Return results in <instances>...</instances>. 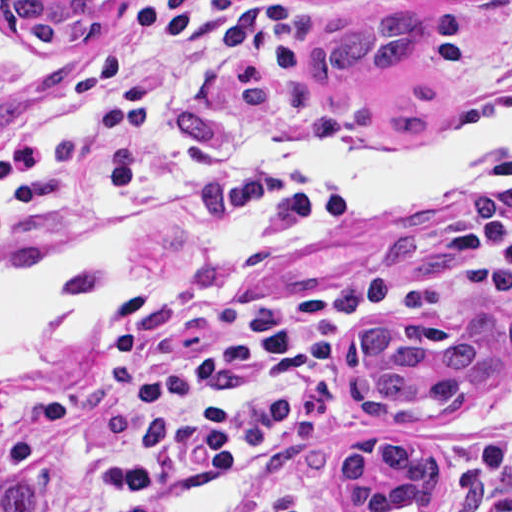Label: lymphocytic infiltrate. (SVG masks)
<instances>
[{
  "mask_svg": "<svg viewBox=\"0 0 512 512\" xmlns=\"http://www.w3.org/2000/svg\"><path fill=\"white\" fill-rule=\"evenodd\" d=\"M298 12L296 0L118 5L92 62L44 122L0 137V246L92 222L122 197L158 199L236 230L278 214L330 218L344 208L346 192L305 164L414 143L388 138L380 125L323 119L293 53ZM510 97L512 32L471 89L442 104L434 132L466 109ZM471 231L480 248L442 277L370 264L325 288L129 335L119 395L130 479L179 486L242 464L265 473L261 512H323L309 477L250 432L247 408L299 386L331 323L407 320L463 288L512 284V205L476 213Z\"/></svg>",
  "mask_w": 512,
  "mask_h": 512,
  "instance_id": "f902f5d3",
  "label": "lymphocytic infiltrate"
}]
</instances>
